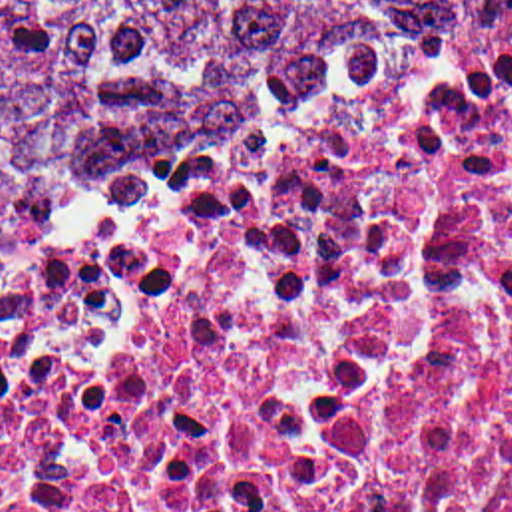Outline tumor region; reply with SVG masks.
Returning <instances> with one entry per match:
<instances>
[{
  "mask_svg": "<svg viewBox=\"0 0 512 512\" xmlns=\"http://www.w3.org/2000/svg\"><path fill=\"white\" fill-rule=\"evenodd\" d=\"M492 0H0V271L348 129Z\"/></svg>",
  "mask_w": 512,
  "mask_h": 512,
  "instance_id": "1",
  "label": "tumor region"
}]
</instances>
